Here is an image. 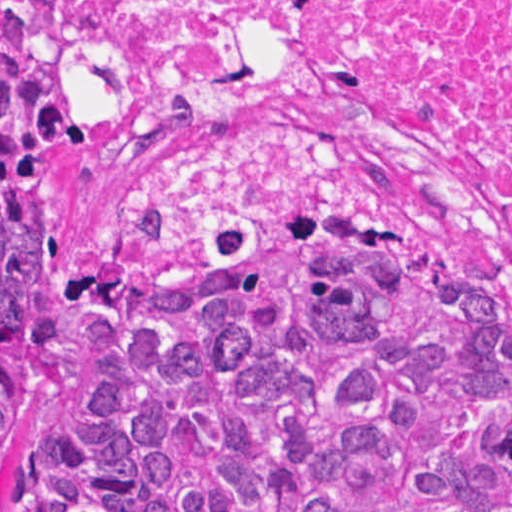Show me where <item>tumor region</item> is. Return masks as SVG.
Instances as JSON below:
<instances>
[{"label": "tumor region", "mask_w": 512, "mask_h": 512, "mask_svg": "<svg viewBox=\"0 0 512 512\" xmlns=\"http://www.w3.org/2000/svg\"><path fill=\"white\" fill-rule=\"evenodd\" d=\"M75 0H0V410L69 311L96 375L13 512H512V310L399 235L258 271L75 272L40 175L87 144Z\"/></svg>", "instance_id": "1"}]
</instances>
